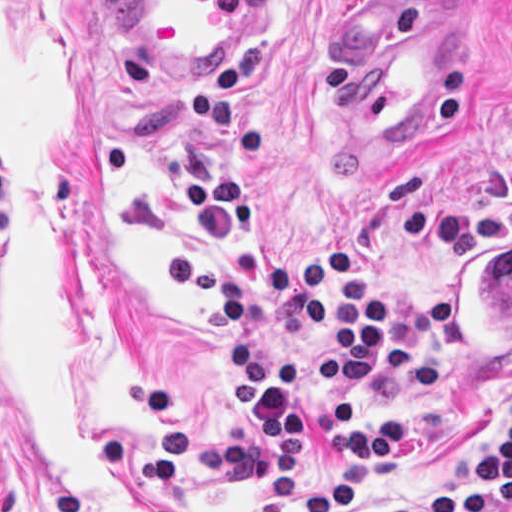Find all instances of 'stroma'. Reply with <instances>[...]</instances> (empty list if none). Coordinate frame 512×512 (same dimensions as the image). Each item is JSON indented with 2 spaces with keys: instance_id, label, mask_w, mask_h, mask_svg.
<instances>
[{
  "instance_id": "obj_1",
  "label": "stroma",
  "mask_w": 512,
  "mask_h": 512,
  "mask_svg": "<svg viewBox=\"0 0 512 512\" xmlns=\"http://www.w3.org/2000/svg\"><path fill=\"white\" fill-rule=\"evenodd\" d=\"M433 1H458L455 80L402 146L356 138L348 36ZM191 176L249 191L285 266L345 243L330 281L363 271L392 312L365 408L400 416L402 445L379 479L353 467L347 512L449 498L480 474L512 419V357L457 377L445 278L461 242L512 232V0H281L217 72L163 66L129 0H0V512H273L232 335L167 293L162 261L206 249L257 297L277 360L319 362V334L202 218ZM334 472L320 427L290 512Z\"/></svg>"
}]
</instances>
